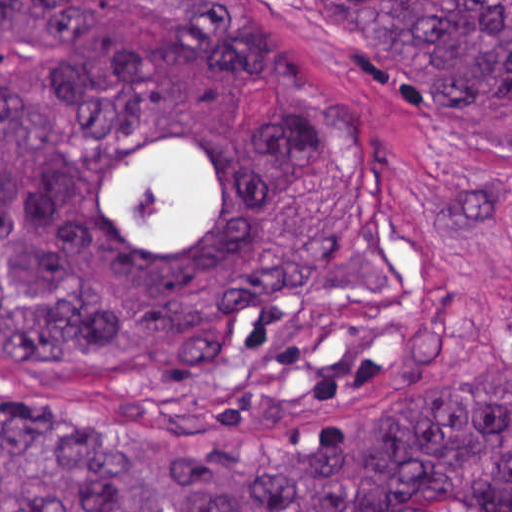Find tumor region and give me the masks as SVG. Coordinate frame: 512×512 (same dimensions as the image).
Instances as JSON below:
<instances>
[{
  "label": "tumor region",
  "instance_id": "e687c5a6",
  "mask_svg": "<svg viewBox=\"0 0 512 512\" xmlns=\"http://www.w3.org/2000/svg\"><path fill=\"white\" fill-rule=\"evenodd\" d=\"M327 37L438 94L512 89V0H304ZM278 85L238 131L245 82ZM195 145L213 219L125 238L109 209L152 141ZM417 235L428 322L351 368L263 344L296 306L398 286L381 244ZM444 252L366 106L320 82L256 0H0V355L106 375L114 430L0 369V512H512V372L339 425L452 347Z\"/></svg>",
  "mask_w": 512,
  "mask_h": 512
}]
</instances>
